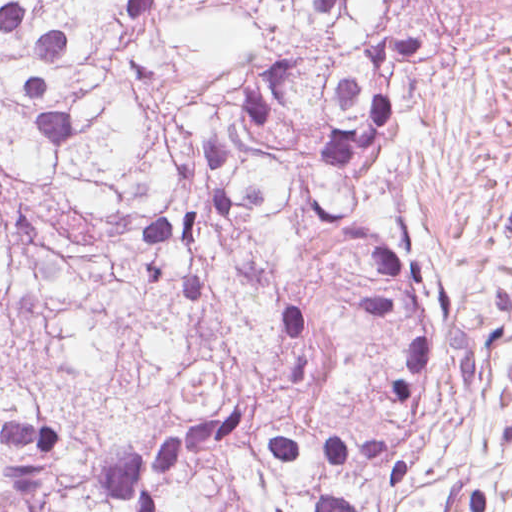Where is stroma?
I'll use <instances>...</instances> for the list:
<instances>
[{
  "instance_id": "obj_1",
  "label": "stroma",
  "mask_w": 512,
  "mask_h": 512,
  "mask_svg": "<svg viewBox=\"0 0 512 512\" xmlns=\"http://www.w3.org/2000/svg\"><path fill=\"white\" fill-rule=\"evenodd\" d=\"M397 196L435 258L498 262L509 311L483 377L430 388L406 478L368 512H512V12L421 68Z\"/></svg>"
}]
</instances>
